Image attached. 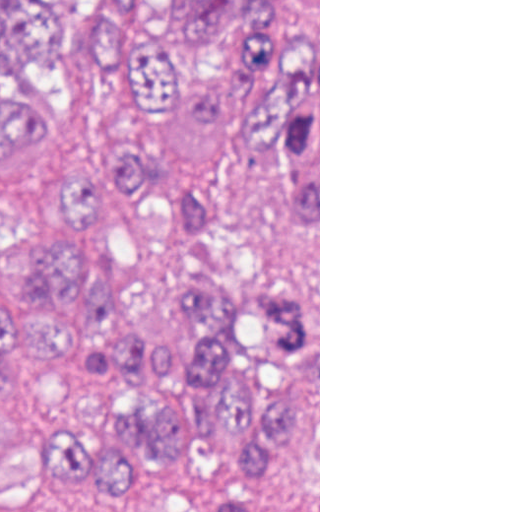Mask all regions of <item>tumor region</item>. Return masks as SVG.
<instances>
[{
  "mask_svg": "<svg viewBox=\"0 0 512 512\" xmlns=\"http://www.w3.org/2000/svg\"><path fill=\"white\" fill-rule=\"evenodd\" d=\"M171 108L197 132L231 112L257 149L318 160V0H0V482L129 491L227 425L251 455L213 512H281L308 296L185 260V338L166 346L81 238L89 210L135 189L216 243L213 194L158 159Z\"/></svg>",
  "mask_w": 512,
  "mask_h": 512,
  "instance_id": "1",
  "label": "tumor region"
}]
</instances>
